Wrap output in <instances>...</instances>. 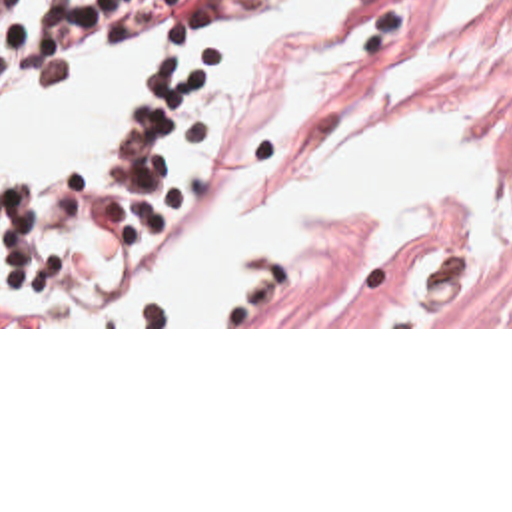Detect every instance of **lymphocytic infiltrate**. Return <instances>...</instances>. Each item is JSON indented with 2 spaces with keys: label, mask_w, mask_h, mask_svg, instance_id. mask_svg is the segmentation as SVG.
Here are the masks:
<instances>
[{
  "label": "lymphocytic infiltrate",
  "mask_w": 512,
  "mask_h": 512,
  "mask_svg": "<svg viewBox=\"0 0 512 512\" xmlns=\"http://www.w3.org/2000/svg\"><path fill=\"white\" fill-rule=\"evenodd\" d=\"M293 0H0V103L82 67L100 36L156 34L158 57L126 101L110 183L52 173L0 189V327H66L166 211L173 131L209 73V32L257 24Z\"/></svg>",
  "instance_id": "lymphocytic-infiltrate-1"
}]
</instances>
